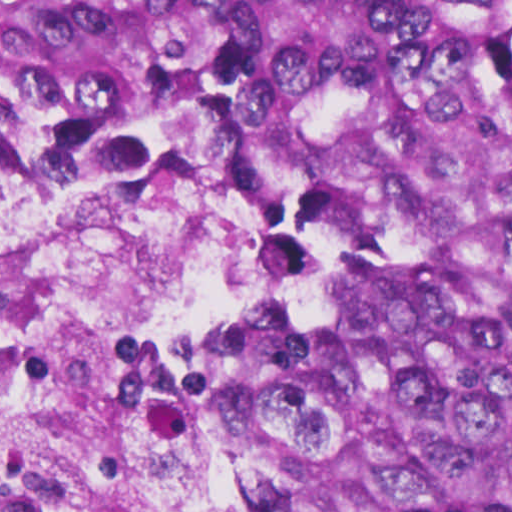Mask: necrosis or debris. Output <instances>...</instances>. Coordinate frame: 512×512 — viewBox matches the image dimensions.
Listing matches in <instances>:
<instances>
[{"mask_svg":"<svg viewBox=\"0 0 512 512\" xmlns=\"http://www.w3.org/2000/svg\"><path fill=\"white\" fill-rule=\"evenodd\" d=\"M238 294V204L29 171L0 228V512H183L168 379Z\"/></svg>","mask_w":512,"mask_h":512,"instance_id":"1","label":"necrosis or debris"}]
</instances>
